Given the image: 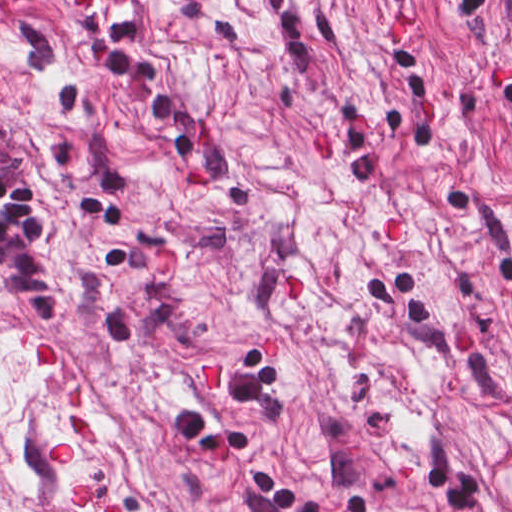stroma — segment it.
Listing matches in <instances>:
<instances>
[{"instance_id": "35a3bbf8", "label": "stroma", "mask_w": 512, "mask_h": 512, "mask_svg": "<svg viewBox=\"0 0 512 512\" xmlns=\"http://www.w3.org/2000/svg\"><path fill=\"white\" fill-rule=\"evenodd\" d=\"M80 488L125 512H512V452L0 0V512H105Z\"/></svg>"}]
</instances>
